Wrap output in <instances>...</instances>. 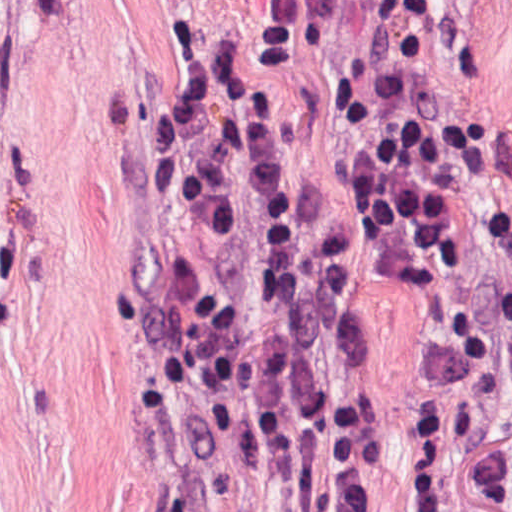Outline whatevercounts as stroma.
<instances>
[{
	"instance_id": "1",
	"label": "stroma",
	"mask_w": 512,
	"mask_h": 512,
	"mask_svg": "<svg viewBox=\"0 0 512 512\" xmlns=\"http://www.w3.org/2000/svg\"><path fill=\"white\" fill-rule=\"evenodd\" d=\"M174 1L350 203L339 94L409 35L511 235L410 295L354 211L359 370L384 443L373 512H512V0H0V512H171L120 333L158 258L139 141L180 86Z\"/></svg>"
}]
</instances>
